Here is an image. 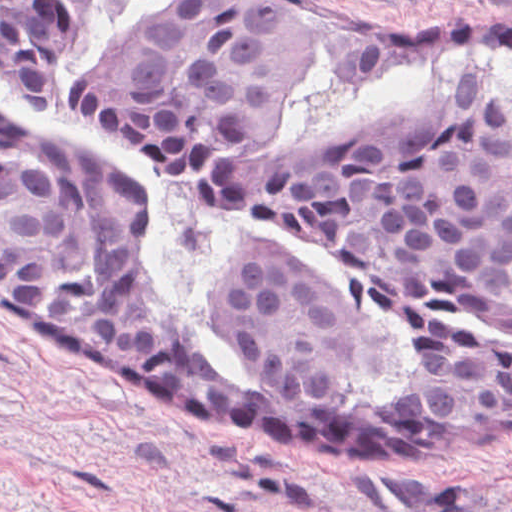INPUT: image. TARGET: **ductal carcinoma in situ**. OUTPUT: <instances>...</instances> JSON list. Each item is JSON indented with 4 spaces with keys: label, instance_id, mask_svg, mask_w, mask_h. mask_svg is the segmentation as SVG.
<instances>
[{
    "label": "ductal carcinoma in situ",
    "instance_id": "obj_1",
    "mask_svg": "<svg viewBox=\"0 0 512 512\" xmlns=\"http://www.w3.org/2000/svg\"><path fill=\"white\" fill-rule=\"evenodd\" d=\"M96 0H0V69L38 112L59 108ZM455 40L512 28L358 36L269 0H171L72 92L103 136L203 204L271 215L339 256L411 329V378L356 398L375 335L365 312L280 246L241 242L202 286L247 353L212 369L150 282L157 220L109 157L36 140L0 106V297L112 351L239 402L357 430H512V94L469 75L314 135L280 134L318 42L351 80L425 66Z\"/></svg>",
    "mask_w": 512,
    "mask_h": 512
}]
</instances>
